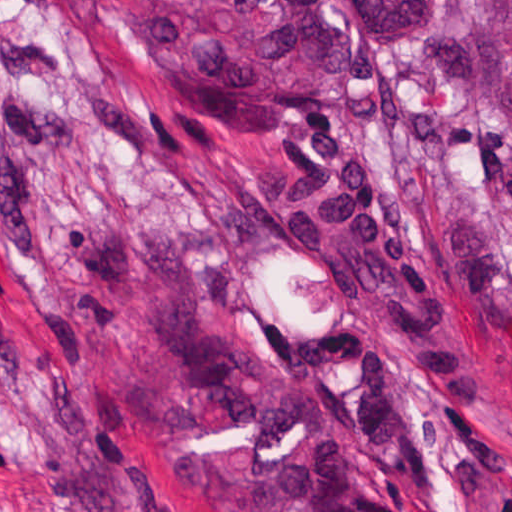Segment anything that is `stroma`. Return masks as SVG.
I'll return each instance as SVG.
<instances>
[{"label":"stroma","mask_w":512,"mask_h":512,"mask_svg":"<svg viewBox=\"0 0 512 512\" xmlns=\"http://www.w3.org/2000/svg\"><path fill=\"white\" fill-rule=\"evenodd\" d=\"M223 109L109 0H0V512H512L486 179L428 41Z\"/></svg>","instance_id":"stroma-1"}]
</instances>
